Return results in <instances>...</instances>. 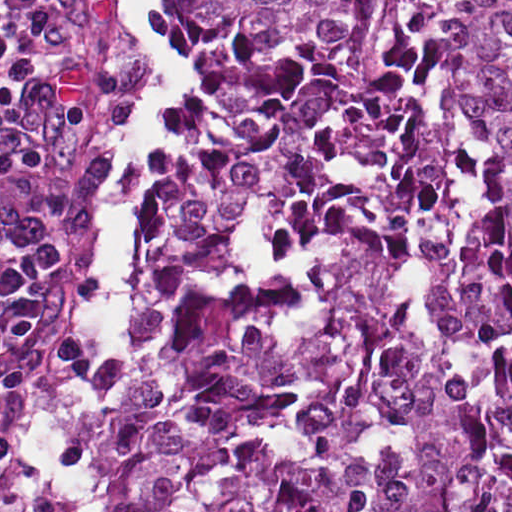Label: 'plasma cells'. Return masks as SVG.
Masks as SVG:
<instances>
[{
  "label": "plasma cells",
  "instance_id": "obj_1",
  "mask_svg": "<svg viewBox=\"0 0 512 512\" xmlns=\"http://www.w3.org/2000/svg\"><path fill=\"white\" fill-rule=\"evenodd\" d=\"M27 1L0 0V512H87L97 397L55 339L77 229L64 155L21 79Z\"/></svg>",
  "mask_w": 512,
  "mask_h": 512
}]
</instances>
